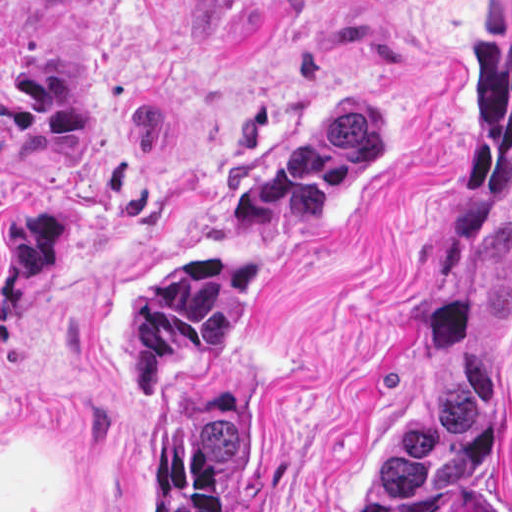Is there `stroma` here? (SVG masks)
<instances>
[{
    "label": "stroma",
    "instance_id": "35a3bbf8",
    "mask_svg": "<svg viewBox=\"0 0 512 512\" xmlns=\"http://www.w3.org/2000/svg\"><path fill=\"white\" fill-rule=\"evenodd\" d=\"M387 156L313 222L237 208L322 120ZM512 213V0H0V512H166L124 288L227 246L267 282L215 348L233 512H347L394 428L421 285ZM468 512H512V329Z\"/></svg>",
    "mask_w": 512,
    "mask_h": 512
}]
</instances>
